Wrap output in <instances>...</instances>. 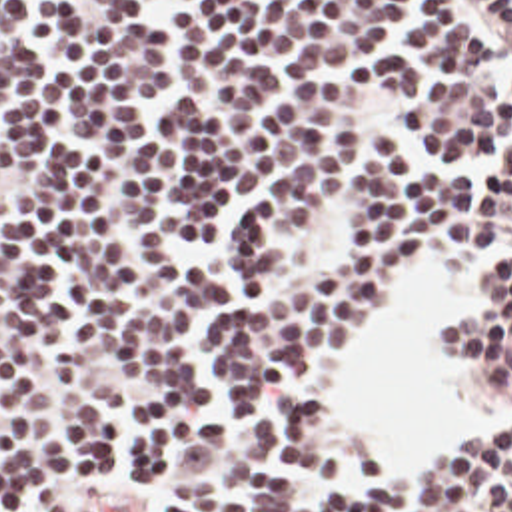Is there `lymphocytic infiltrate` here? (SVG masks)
I'll return each instance as SVG.
<instances>
[{"label": "lymphocytic infiltrate", "mask_w": 512, "mask_h": 512, "mask_svg": "<svg viewBox=\"0 0 512 512\" xmlns=\"http://www.w3.org/2000/svg\"><path fill=\"white\" fill-rule=\"evenodd\" d=\"M512 0H0V512H512V431L356 451L420 259L512 401Z\"/></svg>", "instance_id": "obj_1"}]
</instances>
